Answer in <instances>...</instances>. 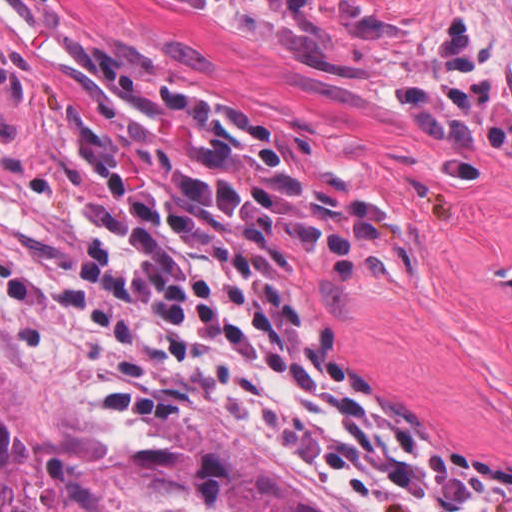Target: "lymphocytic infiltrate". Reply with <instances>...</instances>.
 Listing matches in <instances>:
<instances>
[{
  "label": "lymphocytic infiltrate",
  "instance_id": "1",
  "mask_svg": "<svg viewBox=\"0 0 512 512\" xmlns=\"http://www.w3.org/2000/svg\"><path fill=\"white\" fill-rule=\"evenodd\" d=\"M170 108L177 173L98 165L99 186L78 176L67 194L82 286L196 353L365 512H507L511 467L361 389L310 327L283 249L321 264L368 237L308 162L212 109Z\"/></svg>",
  "mask_w": 512,
  "mask_h": 512
}]
</instances>
